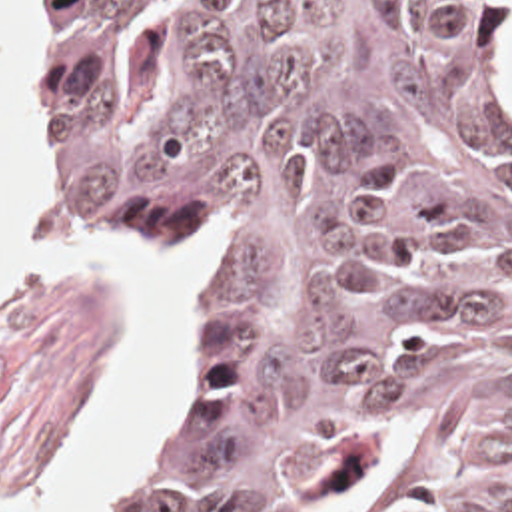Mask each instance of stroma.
<instances>
[{
  "label": "stroma",
  "instance_id": "obj_1",
  "mask_svg": "<svg viewBox=\"0 0 512 512\" xmlns=\"http://www.w3.org/2000/svg\"><path fill=\"white\" fill-rule=\"evenodd\" d=\"M39 7V111L45 155V17ZM496 85L512 119V0H502L496 21ZM51 185L81 231L119 259H169L191 243H207L203 315L197 332L195 370L179 404L161 470L127 512H151L167 478L177 442L207 374L211 352V287L221 263L211 231H163L139 257L119 239L77 215ZM113 331V301L85 291H0V512H27L43 482L55 446L69 438L85 412L99 376L101 356Z\"/></svg>",
  "mask_w": 512,
  "mask_h": 512
}]
</instances>
